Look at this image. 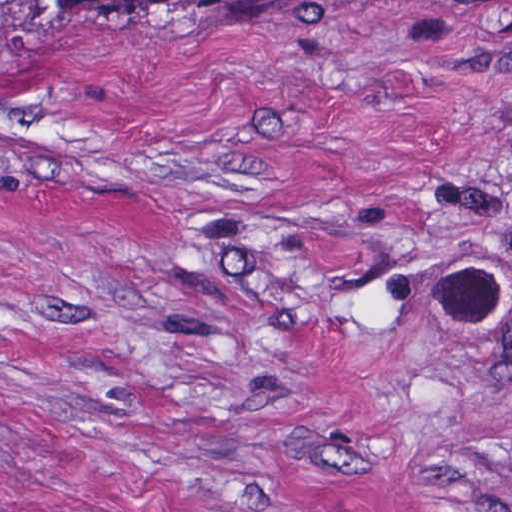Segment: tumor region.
I'll use <instances>...</instances> for the list:
<instances>
[{
  "instance_id": "tumor-region-1",
  "label": "tumor region",
  "mask_w": 512,
  "mask_h": 512,
  "mask_svg": "<svg viewBox=\"0 0 512 512\" xmlns=\"http://www.w3.org/2000/svg\"><path fill=\"white\" fill-rule=\"evenodd\" d=\"M265 1L301 6L316 0H0V67L14 42L39 24L116 2Z\"/></svg>"
}]
</instances>
